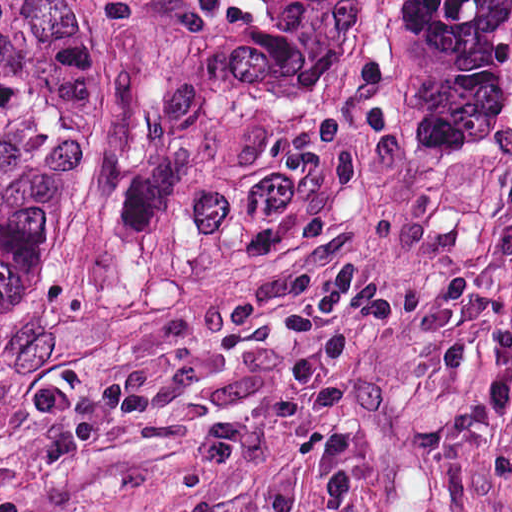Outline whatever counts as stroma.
I'll return each mask as SVG.
<instances>
[{"label": "stroma", "instance_id": "obj_1", "mask_svg": "<svg viewBox=\"0 0 512 512\" xmlns=\"http://www.w3.org/2000/svg\"><path fill=\"white\" fill-rule=\"evenodd\" d=\"M44 1L74 16L39 282L0 310V512H248L414 0H365L338 132L179 110L109 251L130 1Z\"/></svg>", "mask_w": 512, "mask_h": 512}]
</instances>
